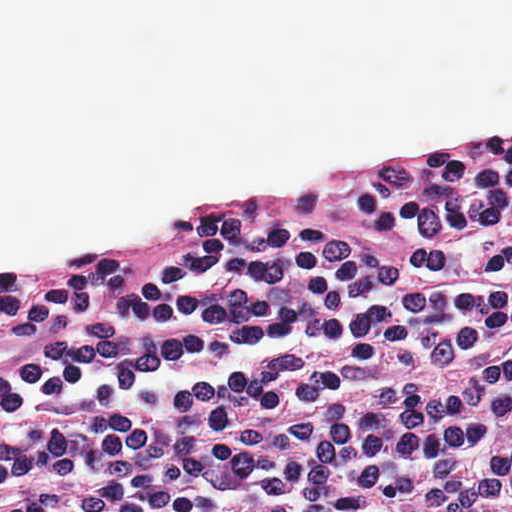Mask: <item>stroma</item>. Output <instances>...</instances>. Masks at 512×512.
<instances>
[{
	"label": "stroma",
	"instance_id": "stroma-1",
	"mask_svg": "<svg viewBox=\"0 0 512 512\" xmlns=\"http://www.w3.org/2000/svg\"><path fill=\"white\" fill-rule=\"evenodd\" d=\"M512 133V122L487 130H450L418 144L338 156L305 165L292 175L277 179H239L208 185L152 219L117 230H96L50 244L35 253L0 257V274L27 265L60 260L82 252L120 244L140 236L168 231L185 219L202 215L230 201H285L316 182L342 174L400 161L445 153L461 146L497 140Z\"/></svg>",
	"mask_w": 512,
	"mask_h": 512
}]
</instances>
